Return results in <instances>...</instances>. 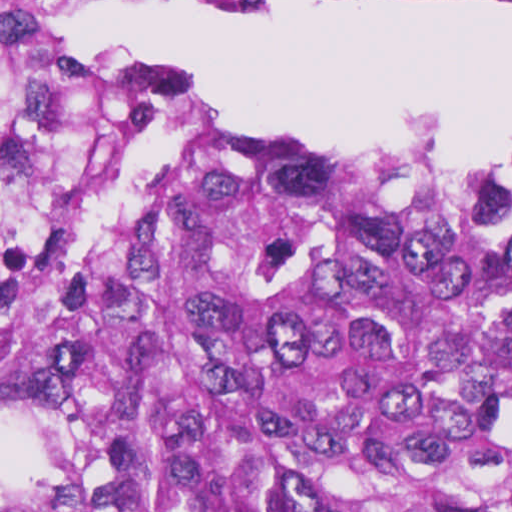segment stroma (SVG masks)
Here are the masks:
<instances>
[{"instance_id":"stroma-1","label":"stroma","mask_w":512,"mask_h":512,"mask_svg":"<svg viewBox=\"0 0 512 512\" xmlns=\"http://www.w3.org/2000/svg\"><path fill=\"white\" fill-rule=\"evenodd\" d=\"M27 1L30 23L40 49L58 57L75 69L92 77H114L76 63L56 48L40 30L37 13L52 7L78 1H94L154 13L193 7L205 3H269L271 1H350L360 7L383 10L410 3H440L457 7H484L512 0H0ZM146 71V70H145ZM141 72L118 77H134ZM306 146L334 156L368 165H476L497 161L512 155V139L496 143L481 154L464 161L444 158H418L355 146H320L304 139H281Z\"/></svg>"}]
</instances>
